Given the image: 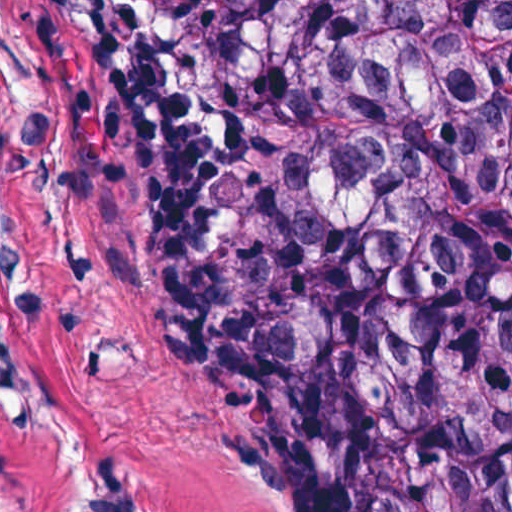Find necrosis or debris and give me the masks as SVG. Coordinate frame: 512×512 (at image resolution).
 Segmentation results:
<instances>
[{
	"mask_svg": "<svg viewBox=\"0 0 512 512\" xmlns=\"http://www.w3.org/2000/svg\"><path fill=\"white\" fill-rule=\"evenodd\" d=\"M505 38L512 52V0H502ZM497 271L512 295V151L501 174L497 196Z\"/></svg>",
	"mask_w": 512,
	"mask_h": 512,
	"instance_id": "necrosis-or-debris-1",
	"label": "necrosis or debris"
}]
</instances>
